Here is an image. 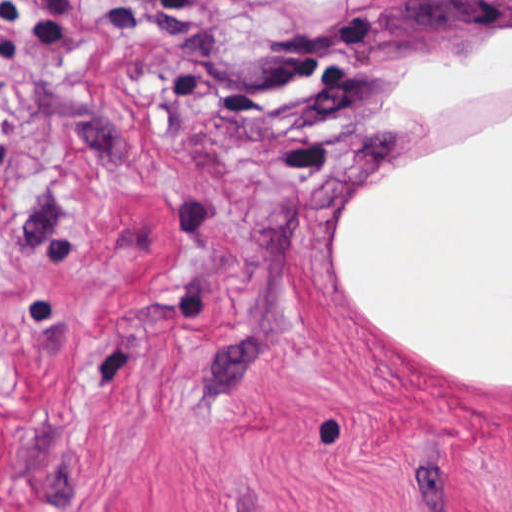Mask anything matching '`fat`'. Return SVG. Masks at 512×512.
<instances>
[{
    "label": "fat",
    "instance_id": "obj_1",
    "mask_svg": "<svg viewBox=\"0 0 512 512\" xmlns=\"http://www.w3.org/2000/svg\"><path fill=\"white\" fill-rule=\"evenodd\" d=\"M512 101V16L379 75V118L430 127ZM366 333L463 388L512 392V112L357 181L330 226Z\"/></svg>",
    "mask_w": 512,
    "mask_h": 512
}]
</instances>
